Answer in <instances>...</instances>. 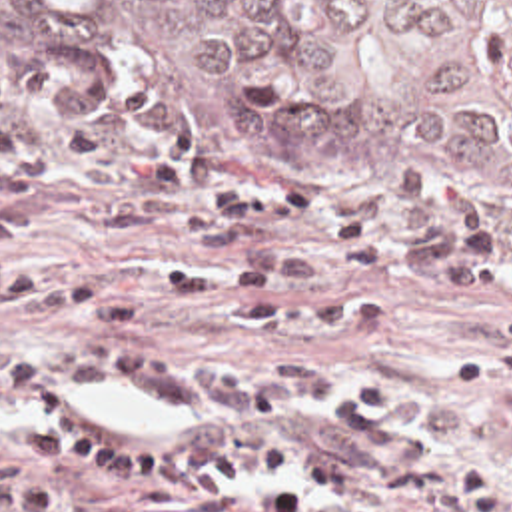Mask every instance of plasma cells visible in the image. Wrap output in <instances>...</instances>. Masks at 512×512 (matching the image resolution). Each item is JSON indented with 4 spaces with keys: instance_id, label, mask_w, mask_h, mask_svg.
<instances>
[{
    "instance_id": "plasma-cells-1",
    "label": "plasma cells",
    "mask_w": 512,
    "mask_h": 512,
    "mask_svg": "<svg viewBox=\"0 0 512 512\" xmlns=\"http://www.w3.org/2000/svg\"><path fill=\"white\" fill-rule=\"evenodd\" d=\"M82 188L88 222L58 226L0 198V312L76 324H132L110 288L20 260L24 238L100 244L180 240L214 250L164 286L200 312L231 284V330L259 356L237 366L154 354H100L38 336L0 346V424H32L18 458L0 460V512H393L431 500L439 472L405 422L397 384L367 372L337 386L321 360H279L275 338L303 328H367L375 298L267 302L273 284H317L329 260L269 240L301 232L359 270L399 264L371 216L343 214L317 188L241 194L212 164L152 142L50 117L0 87V196Z\"/></svg>"
}]
</instances>
